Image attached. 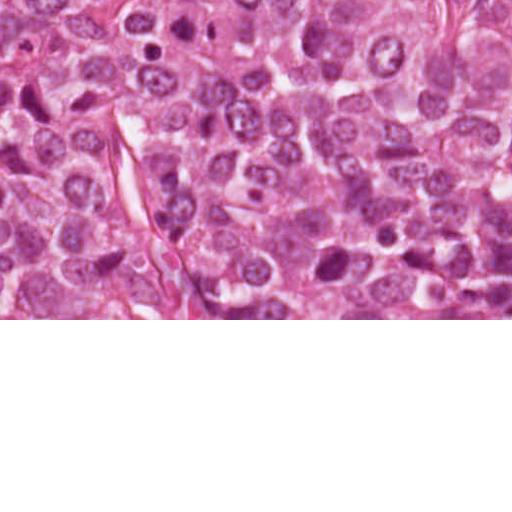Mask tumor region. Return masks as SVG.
<instances>
[{
    "mask_svg": "<svg viewBox=\"0 0 512 512\" xmlns=\"http://www.w3.org/2000/svg\"><path fill=\"white\" fill-rule=\"evenodd\" d=\"M512 318V0H0V319Z\"/></svg>",
    "mask_w": 512,
    "mask_h": 512,
    "instance_id": "1",
    "label": "tumor region"
}]
</instances>
